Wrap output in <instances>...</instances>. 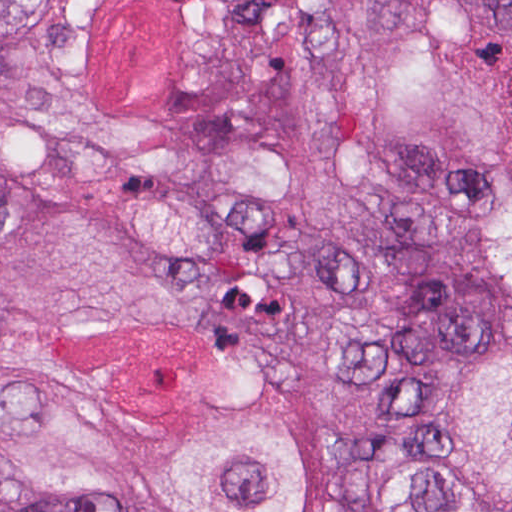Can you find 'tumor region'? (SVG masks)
I'll return each mask as SVG.
<instances>
[{"instance_id":"obj_1","label":"tumor region","mask_w":512,"mask_h":512,"mask_svg":"<svg viewBox=\"0 0 512 512\" xmlns=\"http://www.w3.org/2000/svg\"><path fill=\"white\" fill-rule=\"evenodd\" d=\"M500 310L512 0H0V512H360ZM365 488L512 512V334Z\"/></svg>"}]
</instances>
